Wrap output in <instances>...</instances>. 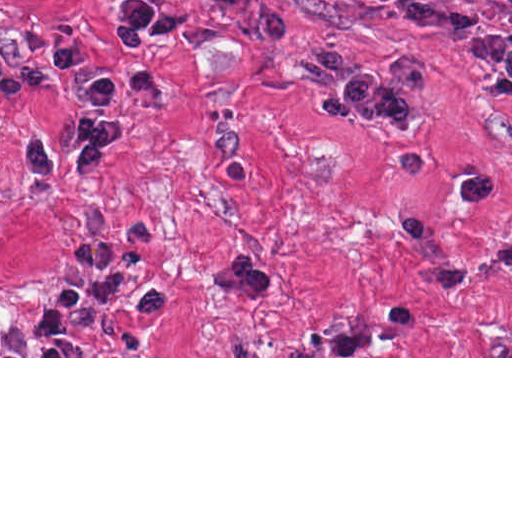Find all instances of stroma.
<instances>
[{"mask_svg": "<svg viewBox=\"0 0 512 512\" xmlns=\"http://www.w3.org/2000/svg\"><path fill=\"white\" fill-rule=\"evenodd\" d=\"M125 1L0 0V358H512V80L359 0H139L206 42L151 39L156 95L114 97L126 130L103 166L39 177L25 140L73 159L84 108L55 40L84 48L82 72L127 71ZM471 1L512 34L511 5ZM333 44L363 72L432 70L418 129L322 118L331 89L296 73ZM75 243L135 245L171 311L104 313L85 356H36ZM236 252L257 298L207 281Z\"/></svg>", "mask_w": 512, "mask_h": 512, "instance_id": "obj_1", "label": "stroma"}]
</instances>
